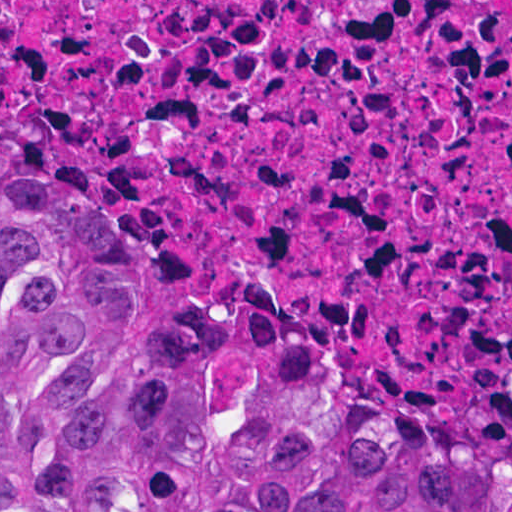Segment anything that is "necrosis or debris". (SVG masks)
Segmentation results:
<instances>
[{"label": "necrosis or debris", "mask_w": 512, "mask_h": 512, "mask_svg": "<svg viewBox=\"0 0 512 512\" xmlns=\"http://www.w3.org/2000/svg\"><path fill=\"white\" fill-rule=\"evenodd\" d=\"M0 108L189 285L512 404V0H0Z\"/></svg>", "instance_id": "necrosis-or-debris-1"}]
</instances>
